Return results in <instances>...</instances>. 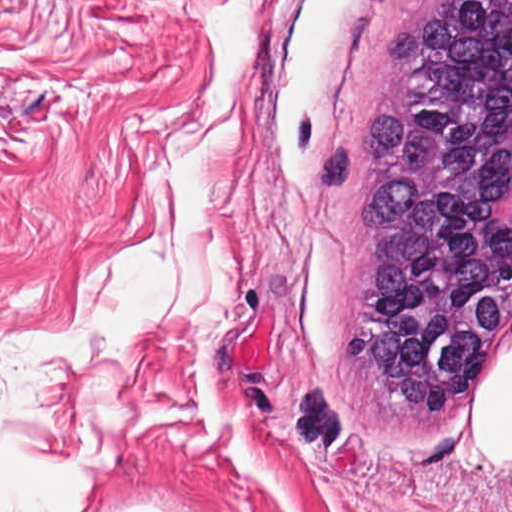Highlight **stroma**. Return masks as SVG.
<instances>
[{"label": "stroma", "instance_id": "35a3bbf8", "mask_svg": "<svg viewBox=\"0 0 512 512\" xmlns=\"http://www.w3.org/2000/svg\"><path fill=\"white\" fill-rule=\"evenodd\" d=\"M220 1L0 0V346L68 330L99 259L151 246L166 158L213 83ZM410 2L257 0L198 158L224 307L61 359L54 428L97 491L79 512H512V467L475 455L467 407L512 324L395 450L339 348L366 186L310 193L329 149L360 140Z\"/></svg>", "mask_w": 512, "mask_h": 512}]
</instances>
